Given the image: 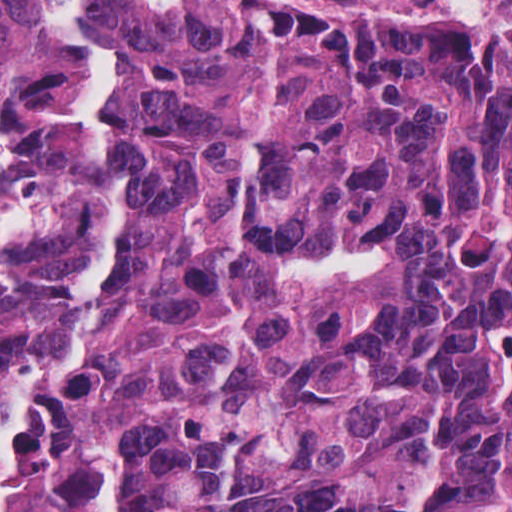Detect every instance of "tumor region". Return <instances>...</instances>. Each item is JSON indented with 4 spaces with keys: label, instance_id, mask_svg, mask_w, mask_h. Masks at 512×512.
Wrapping results in <instances>:
<instances>
[{
    "label": "tumor region",
    "instance_id": "1",
    "mask_svg": "<svg viewBox=\"0 0 512 512\" xmlns=\"http://www.w3.org/2000/svg\"><path fill=\"white\" fill-rule=\"evenodd\" d=\"M512 512V0H0V512Z\"/></svg>",
    "mask_w": 512,
    "mask_h": 512
}]
</instances>
